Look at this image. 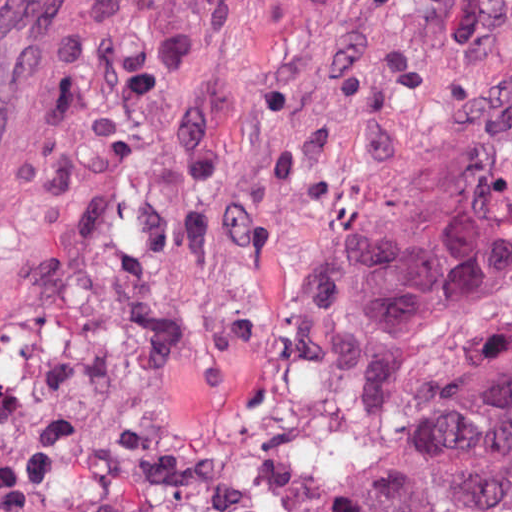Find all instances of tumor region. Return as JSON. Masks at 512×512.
<instances>
[{"instance_id":"obj_1","label":"tumor region","mask_w":512,"mask_h":512,"mask_svg":"<svg viewBox=\"0 0 512 512\" xmlns=\"http://www.w3.org/2000/svg\"><path fill=\"white\" fill-rule=\"evenodd\" d=\"M336 322L354 512H512V99L372 241Z\"/></svg>"}]
</instances>
